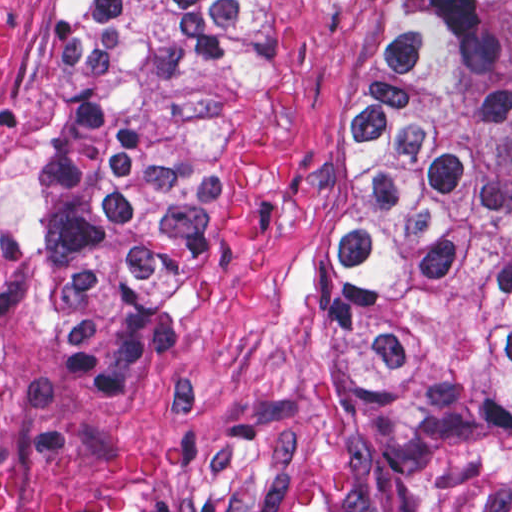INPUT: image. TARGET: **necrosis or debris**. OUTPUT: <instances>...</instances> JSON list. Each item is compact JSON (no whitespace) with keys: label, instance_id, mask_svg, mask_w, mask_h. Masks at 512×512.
<instances>
[{"label":"necrosis or debris","instance_id":"4bbe7bcc","mask_svg":"<svg viewBox=\"0 0 512 512\" xmlns=\"http://www.w3.org/2000/svg\"><path fill=\"white\" fill-rule=\"evenodd\" d=\"M28 0H0V65ZM0 512H225L198 462L116 429L40 415L0 332Z\"/></svg>","mask_w":512,"mask_h":512}]
</instances>
